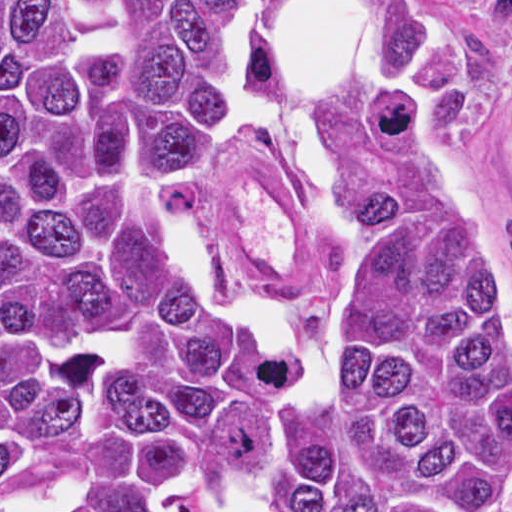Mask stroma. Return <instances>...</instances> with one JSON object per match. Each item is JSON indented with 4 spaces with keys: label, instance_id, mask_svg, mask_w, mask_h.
Returning a JSON list of instances; mask_svg holds the SVG:
<instances>
[{
    "label": "stroma",
    "instance_id": "stroma-1",
    "mask_svg": "<svg viewBox=\"0 0 512 512\" xmlns=\"http://www.w3.org/2000/svg\"><path fill=\"white\" fill-rule=\"evenodd\" d=\"M360 1L371 11L376 0ZM414 1L464 100L460 122L441 134L504 248L512 287V37L460 0ZM188 235L217 293L275 328H330L344 306L349 210L346 228L330 226L285 149L239 142L222 121L190 184Z\"/></svg>",
    "mask_w": 512,
    "mask_h": 512
}]
</instances>
